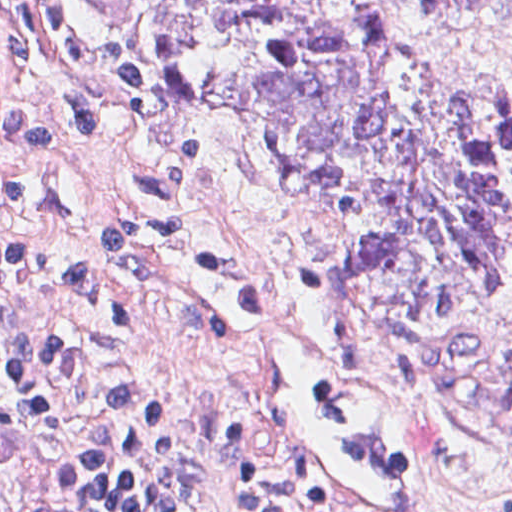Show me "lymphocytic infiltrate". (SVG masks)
Masks as SVG:
<instances>
[{"label":"lymphocytic infiltrate","instance_id":"f902f5d3","mask_svg":"<svg viewBox=\"0 0 512 512\" xmlns=\"http://www.w3.org/2000/svg\"><path fill=\"white\" fill-rule=\"evenodd\" d=\"M61 59L117 106L142 72L84 40L67 0H28ZM0 204L25 205L22 165L47 157L35 111L5 116ZM233 512H302L284 475L215 427ZM213 450L186 385L136 334L95 271L41 245H0V512H209Z\"/></svg>","mask_w":512,"mask_h":512}]
</instances>
